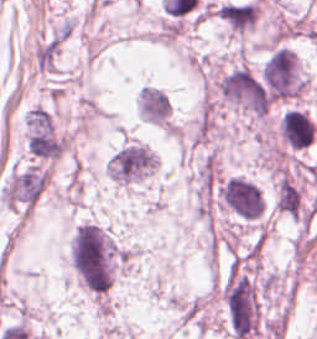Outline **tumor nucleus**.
<instances>
[{"label":"tumor nucleus","instance_id":"obj_1","mask_svg":"<svg viewBox=\"0 0 317 339\" xmlns=\"http://www.w3.org/2000/svg\"><path fill=\"white\" fill-rule=\"evenodd\" d=\"M218 197L225 210L241 220L256 222L263 215V197L246 177H226L219 184Z\"/></svg>","mask_w":317,"mask_h":339},{"label":"tumor nucleus","instance_id":"obj_2","mask_svg":"<svg viewBox=\"0 0 317 339\" xmlns=\"http://www.w3.org/2000/svg\"><path fill=\"white\" fill-rule=\"evenodd\" d=\"M106 166L117 183L128 185L153 172V153L146 144L126 141L113 152Z\"/></svg>","mask_w":317,"mask_h":339}]
</instances>
